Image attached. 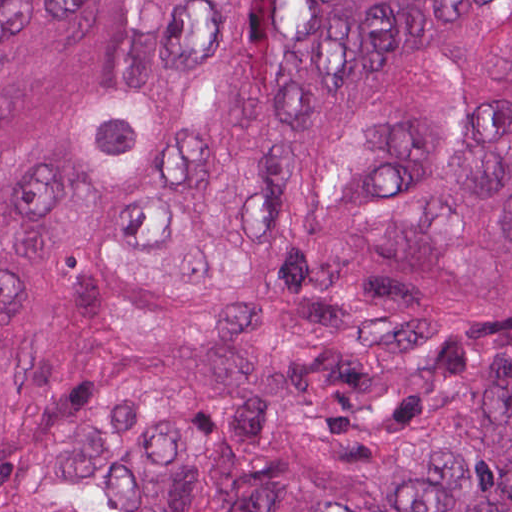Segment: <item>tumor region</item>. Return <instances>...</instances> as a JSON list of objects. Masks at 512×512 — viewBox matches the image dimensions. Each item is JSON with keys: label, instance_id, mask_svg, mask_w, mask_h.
Returning a JSON list of instances; mask_svg holds the SVG:
<instances>
[{"label": "tumor region", "instance_id": "1", "mask_svg": "<svg viewBox=\"0 0 512 512\" xmlns=\"http://www.w3.org/2000/svg\"><path fill=\"white\" fill-rule=\"evenodd\" d=\"M0 512H512V1H0Z\"/></svg>", "mask_w": 512, "mask_h": 512}]
</instances>
